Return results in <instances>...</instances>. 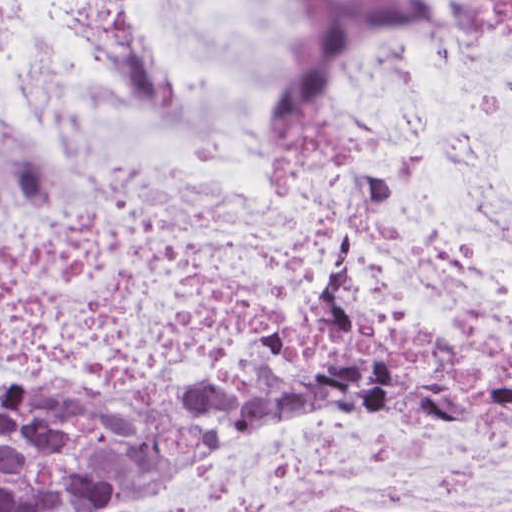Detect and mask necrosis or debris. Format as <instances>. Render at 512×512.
Returning <instances> with one entry per match:
<instances>
[{"label":"necrosis or debris","instance_id":"necrosis-or-debris-1","mask_svg":"<svg viewBox=\"0 0 512 512\" xmlns=\"http://www.w3.org/2000/svg\"><path fill=\"white\" fill-rule=\"evenodd\" d=\"M361 272L512 359V0H0V377L195 401ZM74 512H512V436L269 396Z\"/></svg>","mask_w":512,"mask_h":512}]
</instances>
